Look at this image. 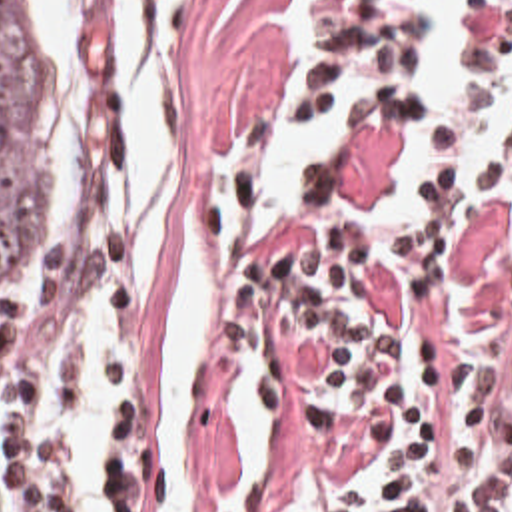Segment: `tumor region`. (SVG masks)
<instances>
[{
  "label": "tumor region",
  "mask_w": 512,
  "mask_h": 512,
  "mask_svg": "<svg viewBox=\"0 0 512 512\" xmlns=\"http://www.w3.org/2000/svg\"><path fill=\"white\" fill-rule=\"evenodd\" d=\"M72 209V99L51 49L0 0V279L55 245Z\"/></svg>",
  "instance_id": "1"
}]
</instances>
